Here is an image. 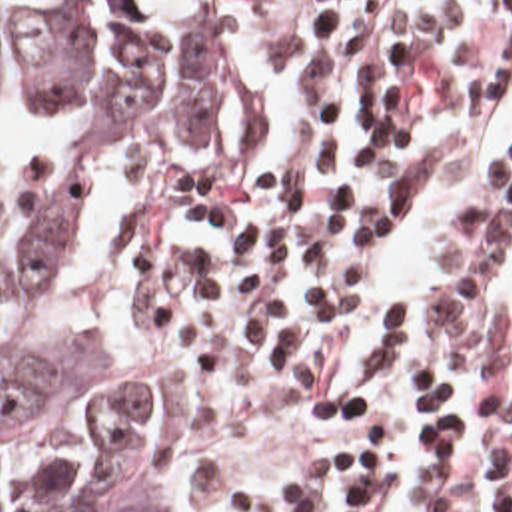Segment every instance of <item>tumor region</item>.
Listing matches in <instances>:
<instances>
[{
  "mask_svg": "<svg viewBox=\"0 0 512 512\" xmlns=\"http://www.w3.org/2000/svg\"><path fill=\"white\" fill-rule=\"evenodd\" d=\"M227 44L223 0H0V84L73 114L0 188V512H175L155 456L165 378L91 358L81 316L43 322L37 306L93 164L203 154Z\"/></svg>",
  "mask_w": 512,
  "mask_h": 512,
  "instance_id": "tumor-region-1",
  "label": "tumor region"
}]
</instances>
